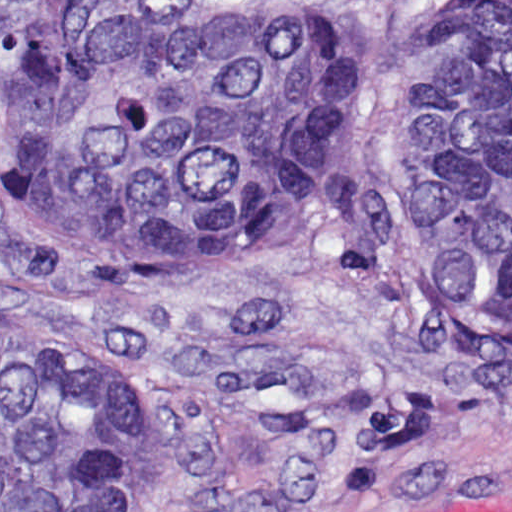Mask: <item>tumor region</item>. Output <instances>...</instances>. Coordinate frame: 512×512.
<instances>
[{"label": "tumor region", "instance_id": "obj_1", "mask_svg": "<svg viewBox=\"0 0 512 512\" xmlns=\"http://www.w3.org/2000/svg\"><path fill=\"white\" fill-rule=\"evenodd\" d=\"M0 0V193L60 272H179L319 217L400 64L383 20ZM416 303L512 327V0H438L394 106ZM0 335V512H135L121 355Z\"/></svg>", "mask_w": 512, "mask_h": 512}]
</instances>
